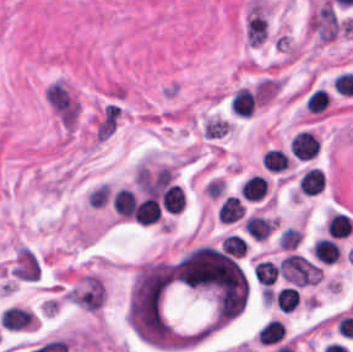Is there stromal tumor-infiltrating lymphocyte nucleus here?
Listing matches in <instances>:
<instances>
[{
  "label": "stromal tumor-infiltrating lymphocyte nucleus",
  "instance_id": "2",
  "mask_svg": "<svg viewBox=\"0 0 353 352\" xmlns=\"http://www.w3.org/2000/svg\"><path fill=\"white\" fill-rule=\"evenodd\" d=\"M269 184L265 177L253 174L239 187L242 198L247 201H260L267 193Z\"/></svg>",
  "mask_w": 353,
  "mask_h": 352
},
{
  "label": "stromal tumor-infiltrating lymphocyte nucleus",
  "instance_id": "6",
  "mask_svg": "<svg viewBox=\"0 0 353 352\" xmlns=\"http://www.w3.org/2000/svg\"><path fill=\"white\" fill-rule=\"evenodd\" d=\"M244 214V206L235 196H228L217 211V219L223 224H230L238 220Z\"/></svg>",
  "mask_w": 353,
  "mask_h": 352
},
{
  "label": "stromal tumor-infiltrating lymphocyte nucleus",
  "instance_id": "1",
  "mask_svg": "<svg viewBox=\"0 0 353 352\" xmlns=\"http://www.w3.org/2000/svg\"><path fill=\"white\" fill-rule=\"evenodd\" d=\"M318 149L319 142L315 134L308 130L295 133L290 142V152L297 159H310Z\"/></svg>",
  "mask_w": 353,
  "mask_h": 352
},
{
  "label": "stromal tumor-infiltrating lymphocyte nucleus",
  "instance_id": "11",
  "mask_svg": "<svg viewBox=\"0 0 353 352\" xmlns=\"http://www.w3.org/2000/svg\"><path fill=\"white\" fill-rule=\"evenodd\" d=\"M329 105V95L324 88H317L308 97L307 107L313 113H320Z\"/></svg>",
  "mask_w": 353,
  "mask_h": 352
},
{
  "label": "stromal tumor-infiltrating lymphocyte nucleus",
  "instance_id": "3",
  "mask_svg": "<svg viewBox=\"0 0 353 352\" xmlns=\"http://www.w3.org/2000/svg\"><path fill=\"white\" fill-rule=\"evenodd\" d=\"M274 224L275 219L249 216L243 223L242 228L252 240L264 241L269 236Z\"/></svg>",
  "mask_w": 353,
  "mask_h": 352
},
{
  "label": "stromal tumor-infiltrating lymphocyte nucleus",
  "instance_id": "12",
  "mask_svg": "<svg viewBox=\"0 0 353 352\" xmlns=\"http://www.w3.org/2000/svg\"><path fill=\"white\" fill-rule=\"evenodd\" d=\"M221 249L240 258L245 255L246 243L231 234L222 239Z\"/></svg>",
  "mask_w": 353,
  "mask_h": 352
},
{
  "label": "stromal tumor-infiltrating lymphocyte nucleus",
  "instance_id": "4",
  "mask_svg": "<svg viewBox=\"0 0 353 352\" xmlns=\"http://www.w3.org/2000/svg\"><path fill=\"white\" fill-rule=\"evenodd\" d=\"M340 252V247L332 238L320 237L312 246V254L322 263H334Z\"/></svg>",
  "mask_w": 353,
  "mask_h": 352
},
{
  "label": "stromal tumor-infiltrating lymphocyte nucleus",
  "instance_id": "8",
  "mask_svg": "<svg viewBox=\"0 0 353 352\" xmlns=\"http://www.w3.org/2000/svg\"><path fill=\"white\" fill-rule=\"evenodd\" d=\"M255 282L271 286L278 274V266L275 262L258 260L252 269Z\"/></svg>",
  "mask_w": 353,
  "mask_h": 352
},
{
  "label": "stromal tumor-infiltrating lymphocyte nucleus",
  "instance_id": "7",
  "mask_svg": "<svg viewBox=\"0 0 353 352\" xmlns=\"http://www.w3.org/2000/svg\"><path fill=\"white\" fill-rule=\"evenodd\" d=\"M135 198L131 191L119 189L113 196V210L119 218H132Z\"/></svg>",
  "mask_w": 353,
  "mask_h": 352
},
{
  "label": "stromal tumor-infiltrating lymphocyte nucleus",
  "instance_id": "5",
  "mask_svg": "<svg viewBox=\"0 0 353 352\" xmlns=\"http://www.w3.org/2000/svg\"><path fill=\"white\" fill-rule=\"evenodd\" d=\"M325 184V177L316 168H309L298 179V191L303 195H316Z\"/></svg>",
  "mask_w": 353,
  "mask_h": 352
},
{
  "label": "stromal tumor-infiltrating lymphocyte nucleus",
  "instance_id": "9",
  "mask_svg": "<svg viewBox=\"0 0 353 352\" xmlns=\"http://www.w3.org/2000/svg\"><path fill=\"white\" fill-rule=\"evenodd\" d=\"M261 164L266 170L280 172L288 168L289 161L282 149L270 148L265 153Z\"/></svg>",
  "mask_w": 353,
  "mask_h": 352
},
{
  "label": "stromal tumor-infiltrating lymphocyte nucleus",
  "instance_id": "13",
  "mask_svg": "<svg viewBox=\"0 0 353 352\" xmlns=\"http://www.w3.org/2000/svg\"><path fill=\"white\" fill-rule=\"evenodd\" d=\"M300 242V232L293 227H286L279 234V245L281 249L293 250Z\"/></svg>",
  "mask_w": 353,
  "mask_h": 352
},
{
  "label": "stromal tumor-infiltrating lymphocyte nucleus",
  "instance_id": "10",
  "mask_svg": "<svg viewBox=\"0 0 353 352\" xmlns=\"http://www.w3.org/2000/svg\"><path fill=\"white\" fill-rule=\"evenodd\" d=\"M299 294L292 287H284L274 295L276 308L281 312H291L296 309Z\"/></svg>",
  "mask_w": 353,
  "mask_h": 352
}]
</instances>
